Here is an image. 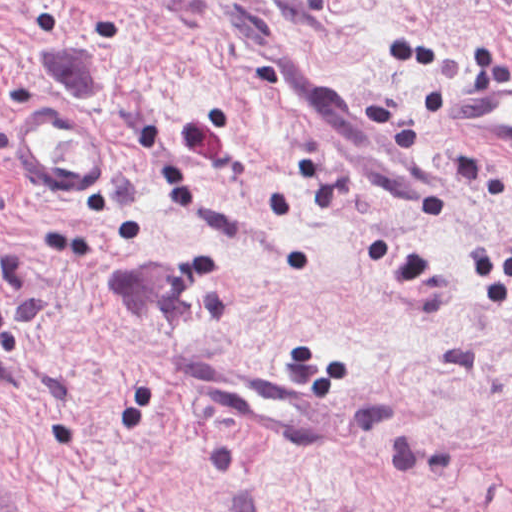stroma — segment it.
I'll return each mask as SVG.
<instances>
[{
    "label": "stroma",
    "instance_id": "1",
    "mask_svg": "<svg viewBox=\"0 0 512 512\" xmlns=\"http://www.w3.org/2000/svg\"><path fill=\"white\" fill-rule=\"evenodd\" d=\"M330 76L455 165L402 229L280 95ZM512 0H0V512H512V146L439 107ZM281 371L334 446L186 392Z\"/></svg>",
    "mask_w": 512,
    "mask_h": 512
}]
</instances>
